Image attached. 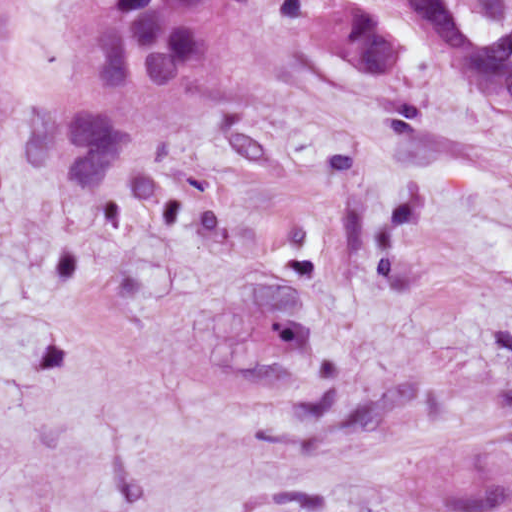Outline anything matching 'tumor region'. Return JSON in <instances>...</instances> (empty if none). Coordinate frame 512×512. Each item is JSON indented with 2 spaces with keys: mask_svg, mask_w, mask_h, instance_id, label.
Listing matches in <instances>:
<instances>
[{
  "mask_svg": "<svg viewBox=\"0 0 512 512\" xmlns=\"http://www.w3.org/2000/svg\"><path fill=\"white\" fill-rule=\"evenodd\" d=\"M248 0H74L60 114H33L21 131L29 162L70 184L101 186L124 159L196 123L210 103L222 25ZM421 30L438 64L463 74L512 112V0H361L306 22L325 50L376 70L401 49L382 18Z\"/></svg>",
  "mask_w": 512,
  "mask_h": 512,
  "instance_id": "tumor-region-1",
  "label": "tumor region"
}]
</instances>
